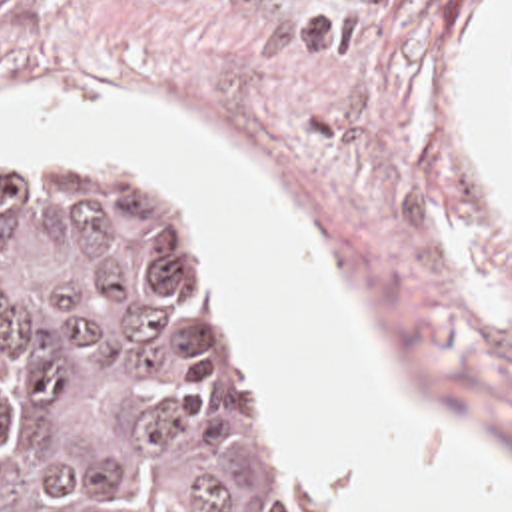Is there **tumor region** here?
Listing matches in <instances>:
<instances>
[{"mask_svg":"<svg viewBox=\"0 0 512 512\" xmlns=\"http://www.w3.org/2000/svg\"><path fill=\"white\" fill-rule=\"evenodd\" d=\"M0 512H304L194 244L114 164L0 152Z\"/></svg>","mask_w":512,"mask_h":512,"instance_id":"e687c5a6","label":"tumor region"}]
</instances>
